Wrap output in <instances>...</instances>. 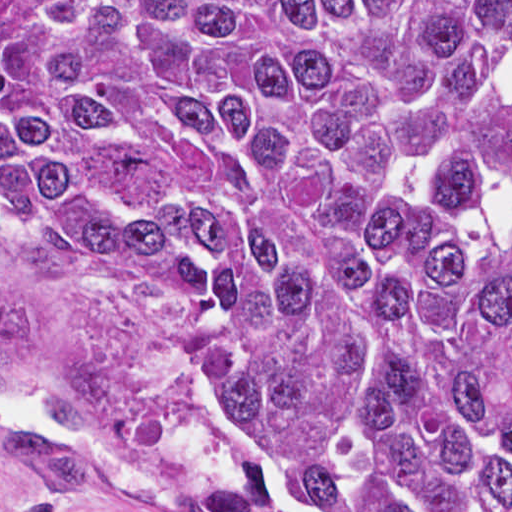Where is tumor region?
I'll return each instance as SVG.
<instances>
[{
	"instance_id": "e687c5a6",
	"label": "tumor region",
	"mask_w": 512,
	"mask_h": 512,
	"mask_svg": "<svg viewBox=\"0 0 512 512\" xmlns=\"http://www.w3.org/2000/svg\"><path fill=\"white\" fill-rule=\"evenodd\" d=\"M0 237L316 511L512 512V1H0ZM36 324L0 392L82 430L112 370L18 368ZM6 436L21 512L96 469Z\"/></svg>"
}]
</instances>
